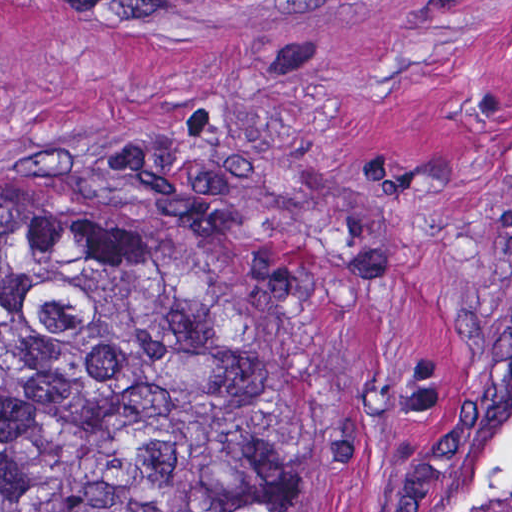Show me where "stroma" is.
Instances as JSON below:
<instances>
[{
    "mask_svg": "<svg viewBox=\"0 0 512 512\" xmlns=\"http://www.w3.org/2000/svg\"><path fill=\"white\" fill-rule=\"evenodd\" d=\"M129 131L297 196L289 512H512V0H0V190Z\"/></svg>",
    "mask_w": 512,
    "mask_h": 512,
    "instance_id": "35a3bbf8",
    "label": "stroma"
}]
</instances>
